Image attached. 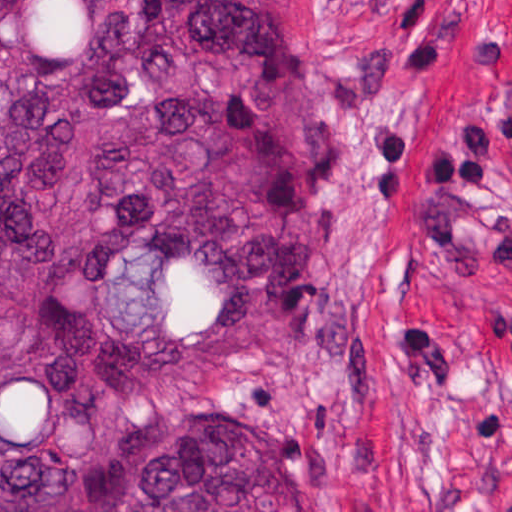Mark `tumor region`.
Returning <instances> with one entry per match:
<instances>
[{
  "label": "tumor region",
  "instance_id": "e687c5a6",
  "mask_svg": "<svg viewBox=\"0 0 512 512\" xmlns=\"http://www.w3.org/2000/svg\"><path fill=\"white\" fill-rule=\"evenodd\" d=\"M302 3L0 0V512H302Z\"/></svg>",
  "mask_w": 512,
  "mask_h": 512
}]
</instances>
